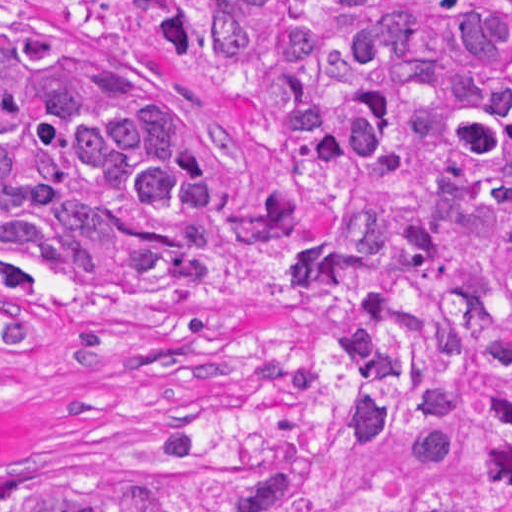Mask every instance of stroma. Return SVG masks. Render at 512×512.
<instances>
[{
	"instance_id": "stroma-1",
	"label": "stroma",
	"mask_w": 512,
	"mask_h": 512,
	"mask_svg": "<svg viewBox=\"0 0 512 512\" xmlns=\"http://www.w3.org/2000/svg\"><path fill=\"white\" fill-rule=\"evenodd\" d=\"M52 12L92 22L175 65L231 125L242 146L234 157L231 223L242 249L229 313L258 329L293 331V278L267 218L309 178L305 156L271 136L243 129L210 91L194 53L177 44L146 0H39ZM39 453H97L98 432L77 389L27 371L0 353V465Z\"/></svg>"
}]
</instances>
